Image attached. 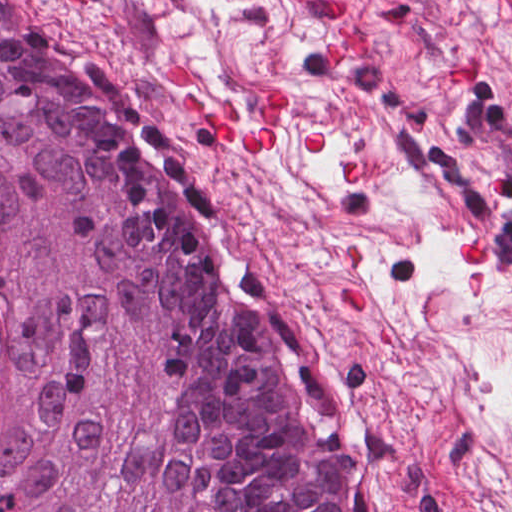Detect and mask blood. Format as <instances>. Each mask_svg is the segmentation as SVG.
<instances>
[{
  "instance_id": "1a1defca",
  "label": "blood",
  "mask_w": 512,
  "mask_h": 512,
  "mask_svg": "<svg viewBox=\"0 0 512 512\" xmlns=\"http://www.w3.org/2000/svg\"><path fill=\"white\" fill-rule=\"evenodd\" d=\"M348 55L368 56V38L353 25L344 27L343 39H331L327 45L331 65L342 63ZM166 76L170 84L184 94L182 105L187 116L227 140L237 155H269L276 150L282 132V89L277 83L259 92L250 107L247 125L239 127L234 101L227 106H217L193 93V82L186 66L176 62L168 66ZM327 147L328 134H306L304 152L322 153ZM463 249L470 263L487 265V253L479 239L468 237ZM342 299L345 305L363 303L361 290L354 287L344 288Z\"/></svg>"
}]
</instances>
